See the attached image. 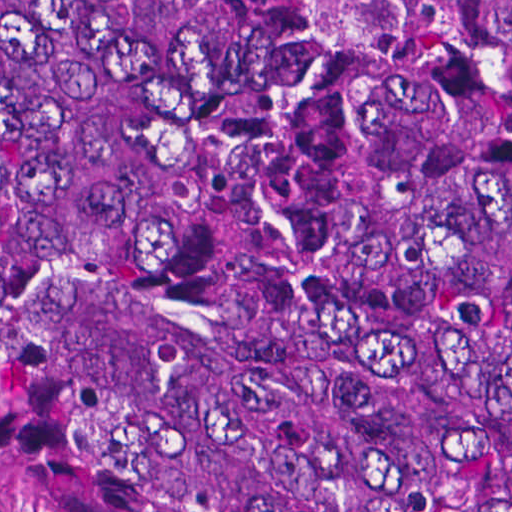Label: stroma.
<instances>
[{"label":"stroma","mask_w":512,"mask_h":512,"mask_svg":"<svg viewBox=\"0 0 512 512\" xmlns=\"http://www.w3.org/2000/svg\"><path fill=\"white\" fill-rule=\"evenodd\" d=\"M0 512H124L60 494H0Z\"/></svg>","instance_id":"obj_1"}]
</instances>
